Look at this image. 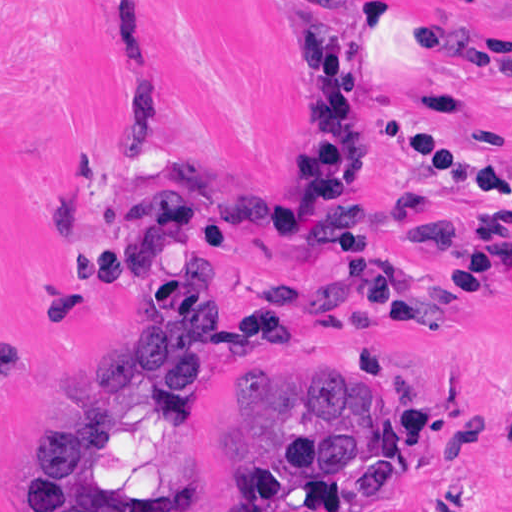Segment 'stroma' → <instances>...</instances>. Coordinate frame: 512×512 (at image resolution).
Returning <instances> with one entry per match:
<instances>
[{
    "label": "stroma",
    "instance_id": "35a3bbf8",
    "mask_svg": "<svg viewBox=\"0 0 512 512\" xmlns=\"http://www.w3.org/2000/svg\"><path fill=\"white\" fill-rule=\"evenodd\" d=\"M366 93L383 158L350 192L376 209L378 256L413 273L418 324L362 333L300 330L253 347L220 342L205 384L160 393L131 375L123 429L94 469L70 475L79 505L95 487L126 512H210L238 462L206 440L238 394V371L277 361L289 378L325 366L366 377L397 500L339 512H512V239L471 293L451 277L491 206L399 152L418 120L496 160L512 184V0H391ZM303 10L343 24L371 8L305 0H0V512H29L33 429L85 419L102 392L97 358L118 318L164 323L204 294L221 300V339L255 292L253 264L217 251L166 255L129 276L144 203L193 187L234 201L259 184L289 236H246L278 278L334 265L298 200L316 148Z\"/></svg>",
    "mask_w": 512,
    "mask_h": 512
}]
</instances>
